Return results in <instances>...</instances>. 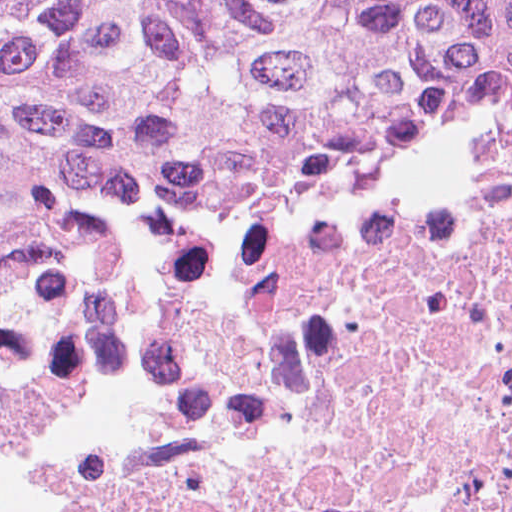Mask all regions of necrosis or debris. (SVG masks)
<instances>
[{
  "mask_svg": "<svg viewBox=\"0 0 512 512\" xmlns=\"http://www.w3.org/2000/svg\"><path fill=\"white\" fill-rule=\"evenodd\" d=\"M0 512H512V132L0 253Z\"/></svg>",
  "mask_w": 512,
  "mask_h": 512,
  "instance_id": "obj_1",
  "label": "necrosis or debris"
}]
</instances>
